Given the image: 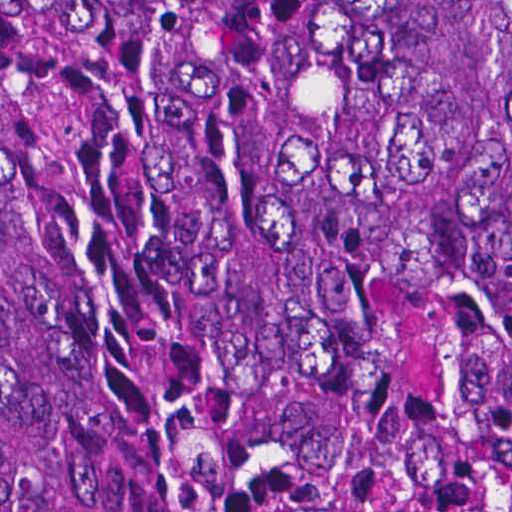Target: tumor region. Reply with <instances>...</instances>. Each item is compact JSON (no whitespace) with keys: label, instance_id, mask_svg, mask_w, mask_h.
I'll return each mask as SVG.
<instances>
[{"label":"tumor region","instance_id":"obj_1","mask_svg":"<svg viewBox=\"0 0 512 512\" xmlns=\"http://www.w3.org/2000/svg\"><path fill=\"white\" fill-rule=\"evenodd\" d=\"M398 284L480 304L512 453V0H0V512L348 456Z\"/></svg>","mask_w":512,"mask_h":512}]
</instances>
